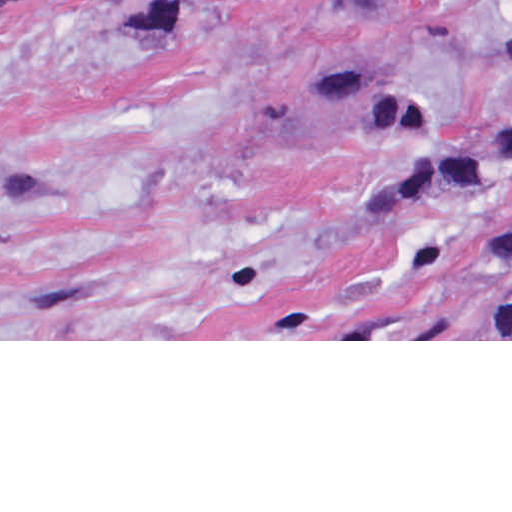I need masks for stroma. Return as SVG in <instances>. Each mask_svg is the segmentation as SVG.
I'll use <instances>...</instances> for the list:
<instances>
[{"label":"stroma","instance_id":"stroma-1","mask_svg":"<svg viewBox=\"0 0 512 512\" xmlns=\"http://www.w3.org/2000/svg\"><path fill=\"white\" fill-rule=\"evenodd\" d=\"M507 1L0 0V341H512Z\"/></svg>","mask_w":512,"mask_h":512}]
</instances>
